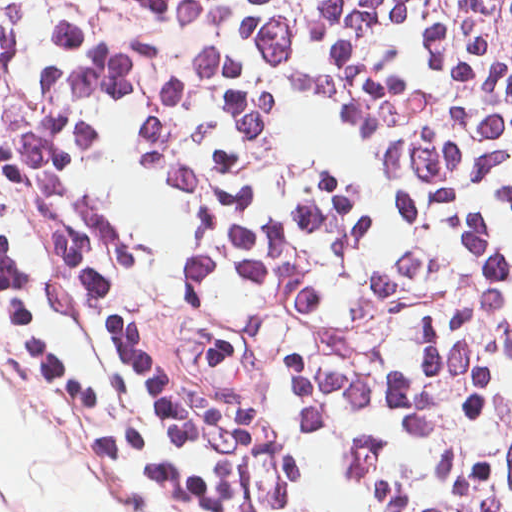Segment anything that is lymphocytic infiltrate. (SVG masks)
<instances>
[{"label": "lymphocytic infiltrate", "instance_id": "1", "mask_svg": "<svg viewBox=\"0 0 512 512\" xmlns=\"http://www.w3.org/2000/svg\"><path fill=\"white\" fill-rule=\"evenodd\" d=\"M0 77L277 512H512V0H0Z\"/></svg>", "mask_w": 512, "mask_h": 512}]
</instances>
